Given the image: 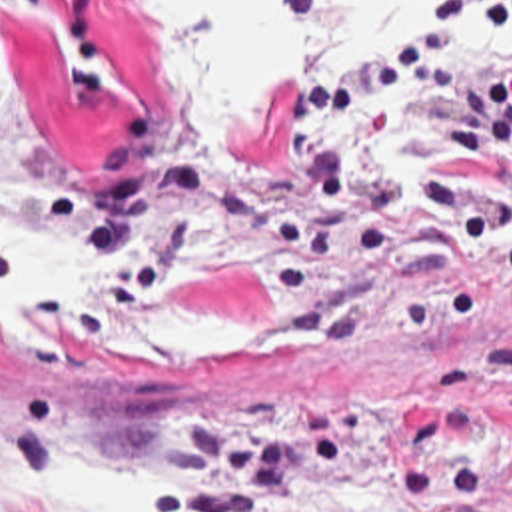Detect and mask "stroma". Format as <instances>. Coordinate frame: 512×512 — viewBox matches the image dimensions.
<instances>
[{
    "instance_id": "35a3bbf8",
    "label": "stroma",
    "mask_w": 512,
    "mask_h": 512,
    "mask_svg": "<svg viewBox=\"0 0 512 512\" xmlns=\"http://www.w3.org/2000/svg\"><path fill=\"white\" fill-rule=\"evenodd\" d=\"M311 0H287L303 29ZM123 0H0V236L108 282L0 318V512L58 458L177 456L149 512H512V0H453L243 140Z\"/></svg>"
}]
</instances>
